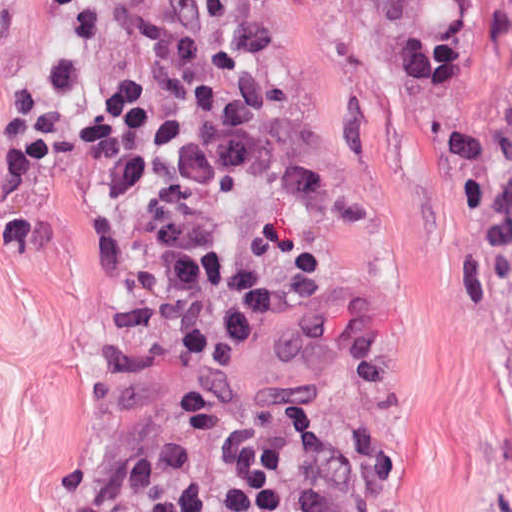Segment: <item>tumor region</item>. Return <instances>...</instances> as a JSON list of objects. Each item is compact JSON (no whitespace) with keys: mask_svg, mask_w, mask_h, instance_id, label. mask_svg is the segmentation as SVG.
Instances as JSON below:
<instances>
[{"mask_svg":"<svg viewBox=\"0 0 512 512\" xmlns=\"http://www.w3.org/2000/svg\"><path fill=\"white\" fill-rule=\"evenodd\" d=\"M481 211L512 354V0H392Z\"/></svg>","mask_w":512,"mask_h":512,"instance_id":"1","label":"tumor region"}]
</instances>
